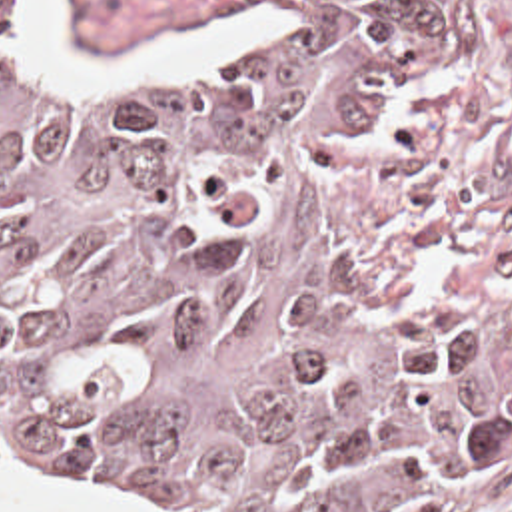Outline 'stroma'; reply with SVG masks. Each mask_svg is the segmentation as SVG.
<instances>
[{"instance_id":"35a3bbf8","label":"stroma","mask_w":512,"mask_h":512,"mask_svg":"<svg viewBox=\"0 0 512 512\" xmlns=\"http://www.w3.org/2000/svg\"><path fill=\"white\" fill-rule=\"evenodd\" d=\"M23 1L11 0L15 43L49 89L130 95L172 85L53 77L21 35ZM274 5L67 0V21L87 51H148L188 37L222 9L258 11L256 43L200 77L268 47ZM352 257L408 317L448 380L506 428V454L488 474L416 512H512V0H436L422 59L356 179ZM0 468L95 504L176 512L85 486L7 446H0Z\"/></svg>"}]
</instances>
